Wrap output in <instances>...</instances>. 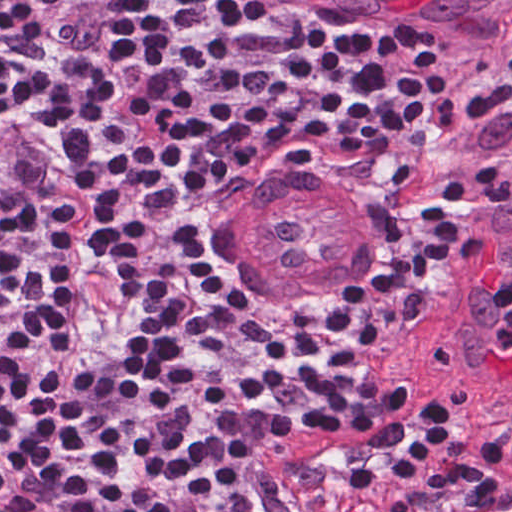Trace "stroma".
<instances>
[{"label":"stroma","instance_id":"35a3bbf8","mask_svg":"<svg viewBox=\"0 0 512 512\" xmlns=\"http://www.w3.org/2000/svg\"><path fill=\"white\" fill-rule=\"evenodd\" d=\"M349 6L363 9L387 32L417 44L453 77L460 101L437 149L393 198L367 184L304 170L273 156L256 157L237 185L261 190L248 185L298 178L322 185L341 202L355 228L356 250L349 260L323 289L301 299L244 306L212 279L199 251L206 209L189 229L183 252L235 318H262L294 307L353 302L380 289L412 286L430 257V243L444 235L452 249L406 296L363 359L373 369L461 380L442 346L446 299L473 262L495 241L512 236V173L489 162L473 140L479 104L512 70V21L459 25L366 2ZM499 391L512 396V390Z\"/></svg>","mask_w":512,"mask_h":512}]
</instances>
